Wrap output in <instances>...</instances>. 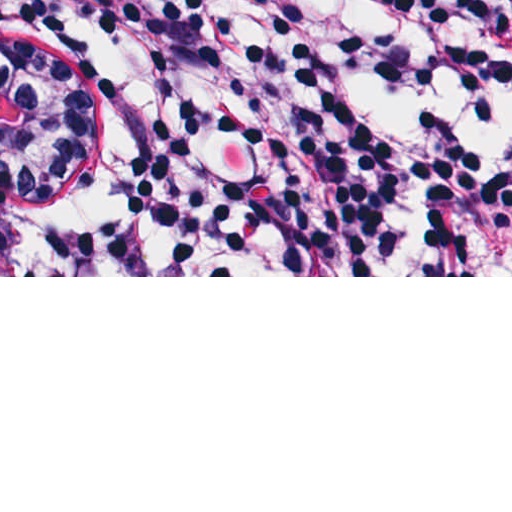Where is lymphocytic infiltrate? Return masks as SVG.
<instances>
[{
	"mask_svg": "<svg viewBox=\"0 0 512 512\" xmlns=\"http://www.w3.org/2000/svg\"><path fill=\"white\" fill-rule=\"evenodd\" d=\"M27 1L0 64L86 149L80 275L512 276V147L356 117L368 84L512 94V0H358L419 49L298 0Z\"/></svg>",
	"mask_w": 512,
	"mask_h": 512,
	"instance_id": "1",
	"label": "lymphocytic infiltrate"
}]
</instances>
